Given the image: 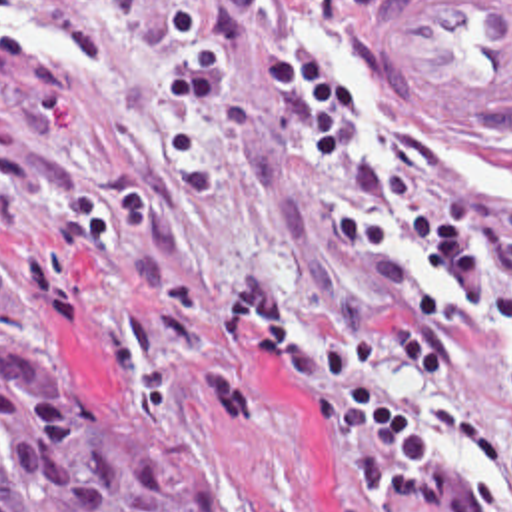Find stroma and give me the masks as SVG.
Wrapping results in <instances>:
<instances>
[{
  "mask_svg": "<svg viewBox=\"0 0 512 512\" xmlns=\"http://www.w3.org/2000/svg\"><path fill=\"white\" fill-rule=\"evenodd\" d=\"M398 0H332L304 58L348 88L358 144L422 134L512 208V124L408 92L388 62ZM282 0H0V351L92 371L206 457L244 512H334L330 435L250 323L260 429L212 417V313L238 283L288 285L304 323H368L306 194L330 174L270 100L260 36ZM445 287L429 258L402 254ZM414 399L457 409L512 461V335L469 317Z\"/></svg>",
  "mask_w": 512,
  "mask_h": 512,
  "instance_id": "35a3bbf8",
  "label": "stroma"
}]
</instances>
